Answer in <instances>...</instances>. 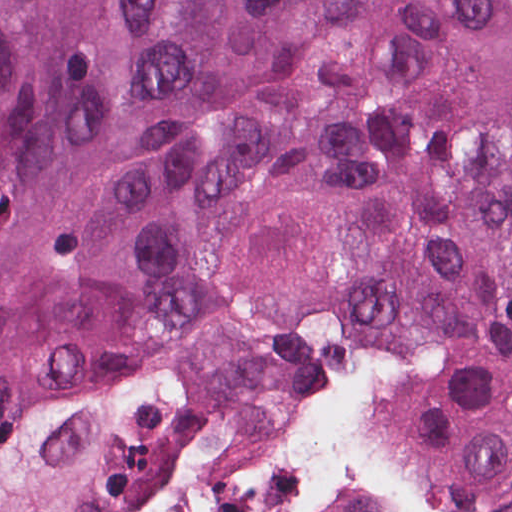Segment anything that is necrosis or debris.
<instances>
[{
	"mask_svg": "<svg viewBox=\"0 0 512 512\" xmlns=\"http://www.w3.org/2000/svg\"><path fill=\"white\" fill-rule=\"evenodd\" d=\"M121 512H365L326 489L288 444L283 389Z\"/></svg>",
	"mask_w": 512,
	"mask_h": 512,
	"instance_id": "4bbe7bcc",
	"label": "necrosis or debris"
}]
</instances>
